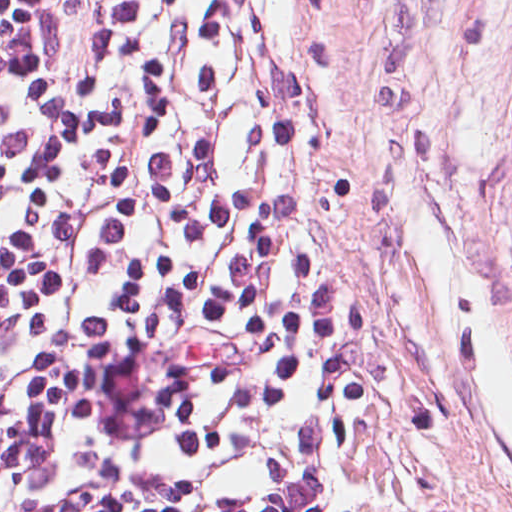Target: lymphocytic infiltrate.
<instances>
[{
    "label": "lymphocytic infiltrate",
    "instance_id": "obj_1",
    "mask_svg": "<svg viewBox=\"0 0 512 512\" xmlns=\"http://www.w3.org/2000/svg\"><path fill=\"white\" fill-rule=\"evenodd\" d=\"M311 0H0V512H390Z\"/></svg>",
    "mask_w": 512,
    "mask_h": 512
}]
</instances>
